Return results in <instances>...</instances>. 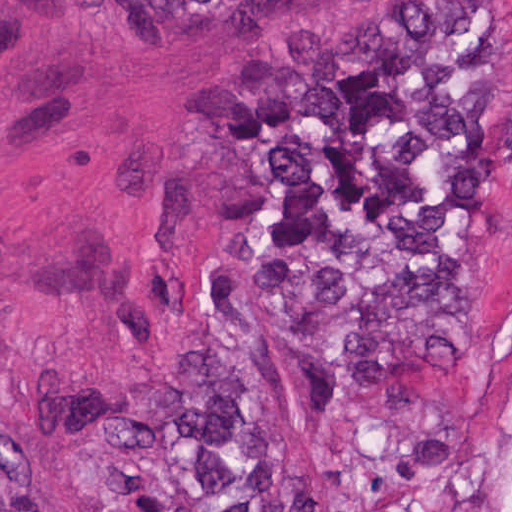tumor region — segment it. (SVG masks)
<instances>
[{
    "label": "tumor region",
    "instance_id": "1",
    "mask_svg": "<svg viewBox=\"0 0 512 512\" xmlns=\"http://www.w3.org/2000/svg\"><path fill=\"white\" fill-rule=\"evenodd\" d=\"M244 28L276 0H152ZM512 122L492 0H420L258 54L180 344L45 379L91 512H512L475 449L490 219ZM0 512H52L0 390Z\"/></svg>",
    "mask_w": 512,
    "mask_h": 512
}]
</instances>
